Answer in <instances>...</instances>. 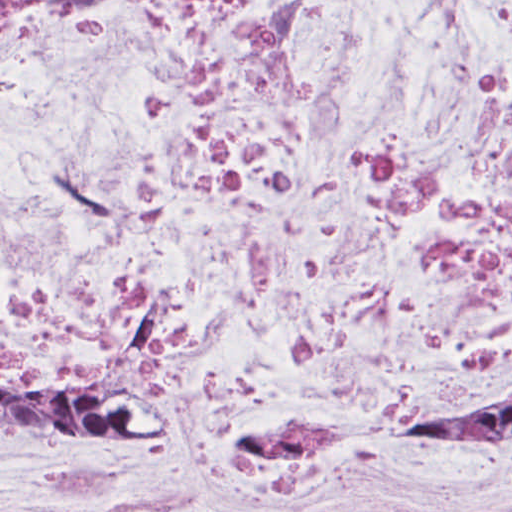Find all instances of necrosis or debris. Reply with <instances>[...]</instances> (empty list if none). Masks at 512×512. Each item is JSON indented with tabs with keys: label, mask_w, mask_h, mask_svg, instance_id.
<instances>
[{
	"label": "necrosis or debris",
	"mask_w": 512,
	"mask_h": 512,
	"mask_svg": "<svg viewBox=\"0 0 512 512\" xmlns=\"http://www.w3.org/2000/svg\"><path fill=\"white\" fill-rule=\"evenodd\" d=\"M0 359L151 429L0 512H512V0H0Z\"/></svg>",
	"instance_id": "4bbe7bcc"
}]
</instances>
